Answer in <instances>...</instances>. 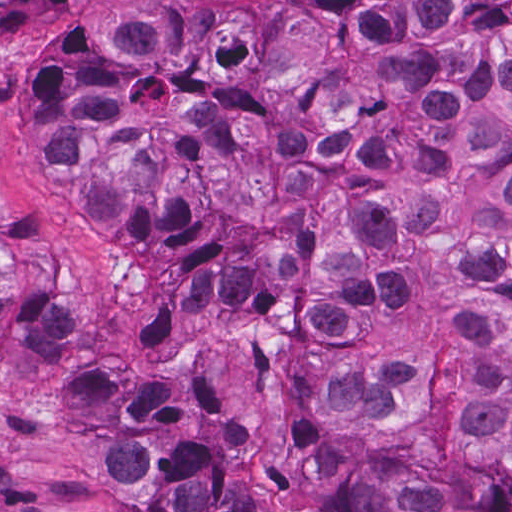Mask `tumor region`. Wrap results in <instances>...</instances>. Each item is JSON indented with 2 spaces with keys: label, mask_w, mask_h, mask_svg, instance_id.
Segmentation results:
<instances>
[{
  "label": "tumor region",
  "mask_w": 512,
  "mask_h": 512,
  "mask_svg": "<svg viewBox=\"0 0 512 512\" xmlns=\"http://www.w3.org/2000/svg\"><path fill=\"white\" fill-rule=\"evenodd\" d=\"M40 140L79 217L292 343L338 512H512V0H100ZM0 343L57 356L111 512H288L216 369L42 310Z\"/></svg>",
  "instance_id": "tumor-region-1"
}]
</instances>
